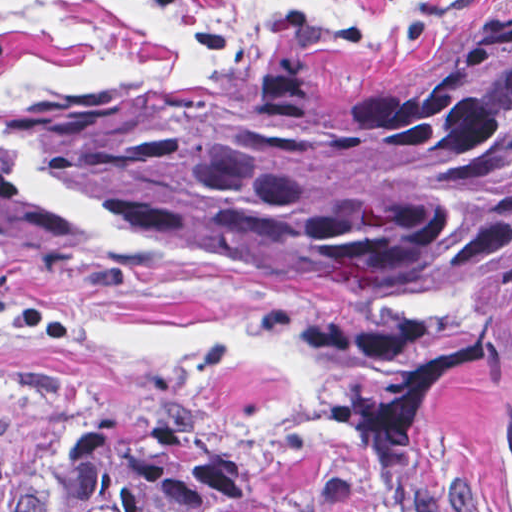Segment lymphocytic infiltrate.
Instances as JSON below:
<instances>
[{"label": "lymphocytic infiltrate", "instance_id": "1", "mask_svg": "<svg viewBox=\"0 0 512 512\" xmlns=\"http://www.w3.org/2000/svg\"><path fill=\"white\" fill-rule=\"evenodd\" d=\"M167 27L196 41L218 68L230 65V39L198 0H141Z\"/></svg>", "mask_w": 512, "mask_h": 512}]
</instances>
